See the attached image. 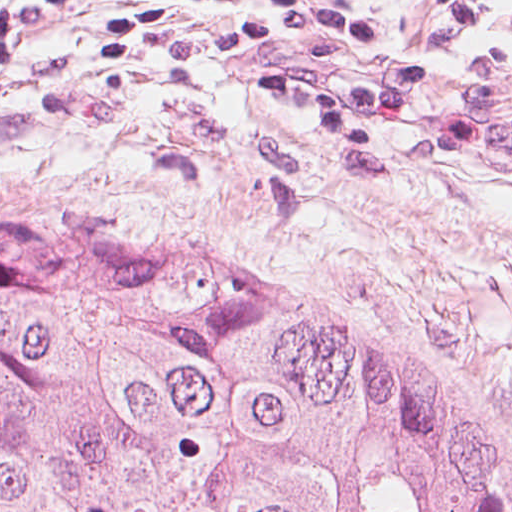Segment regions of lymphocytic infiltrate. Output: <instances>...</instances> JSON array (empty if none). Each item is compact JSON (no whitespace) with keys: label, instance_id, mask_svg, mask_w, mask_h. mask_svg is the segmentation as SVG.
<instances>
[{"label":"lymphocytic infiltrate","instance_id":"lymphocytic-infiltrate-1","mask_svg":"<svg viewBox=\"0 0 512 512\" xmlns=\"http://www.w3.org/2000/svg\"><path fill=\"white\" fill-rule=\"evenodd\" d=\"M470 31L501 0H433ZM191 13L221 33L222 55H272L249 94L318 133L344 167L485 172L476 142L512 134V83L462 78L421 58L370 0H24L0 12V69L19 70L37 37L91 14L85 61L123 66L144 41ZM486 173V172H485Z\"/></svg>","mask_w":512,"mask_h":512}]
</instances>
